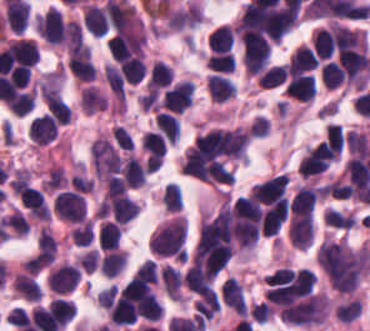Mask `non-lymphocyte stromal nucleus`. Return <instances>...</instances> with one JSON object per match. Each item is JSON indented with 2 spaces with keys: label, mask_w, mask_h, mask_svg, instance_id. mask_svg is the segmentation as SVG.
<instances>
[{
  "label": "non-lymphocyte stromal nucleus",
  "mask_w": 370,
  "mask_h": 331,
  "mask_svg": "<svg viewBox=\"0 0 370 331\" xmlns=\"http://www.w3.org/2000/svg\"><path fill=\"white\" fill-rule=\"evenodd\" d=\"M103 76L112 95L117 101L124 104L125 82L123 72L115 64L107 62Z\"/></svg>",
  "instance_id": "obj_1"
}]
</instances>
